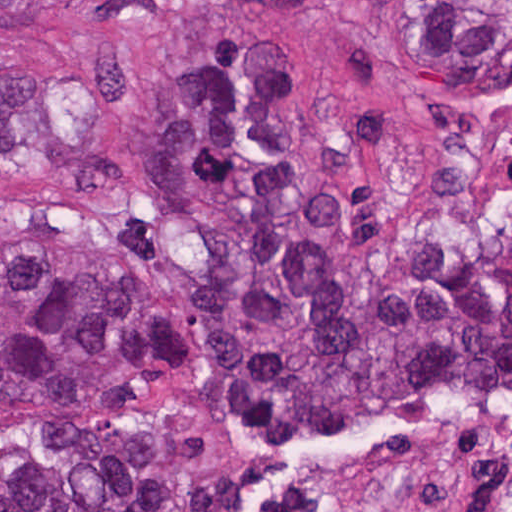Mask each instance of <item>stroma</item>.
I'll return each instance as SVG.
<instances>
[{"mask_svg": "<svg viewBox=\"0 0 512 512\" xmlns=\"http://www.w3.org/2000/svg\"><path fill=\"white\" fill-rule=\"evenodd\" d=\"M205 33L276 44L305 102L311 176L349 213L372 286L436 238L479 227L512 242V89L431 97L405 19L364 0H78L34 26H0V67L38 72L77 140H123L167 51ZM119 197L56 200L0 181V268L93 238ZM131 252L189 361V380L141 410L182 480L234 472L246 512H489L512 489V382L265 464L196 381L192 241L144 214Z\"/></svg>", "mask_w": 512, "mask_h": 512, "instance_id": "35a3bbf8", "label": "stroma"}]
</instances>
